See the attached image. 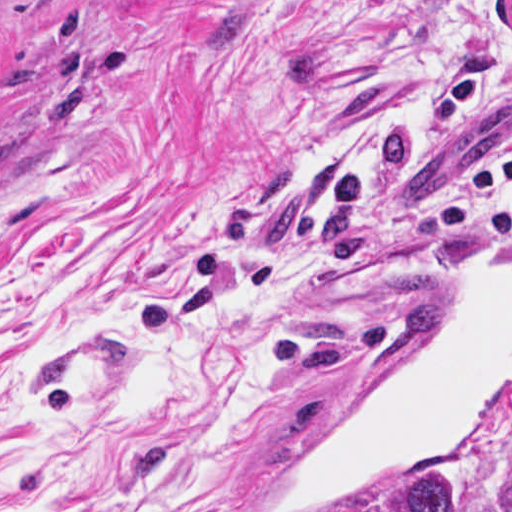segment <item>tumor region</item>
<instances>
[{"instance_id":"obj_1","label":"tumor region","mask_w":512,"mask_h":512,"mask_svg":"<svg viewBox=\"0 0 512 512\" xmlns=\"http://www.w3.org/2000/svg\"><path fill=\"white\" fill-rule=\"evenodd\" d=\"M512 16V0H510ZM456 481L447 473L439 472L419 479L405 495L398 512H454ZM507 512H512V493L507 501Z\"/></svg>"}]
</instances>
